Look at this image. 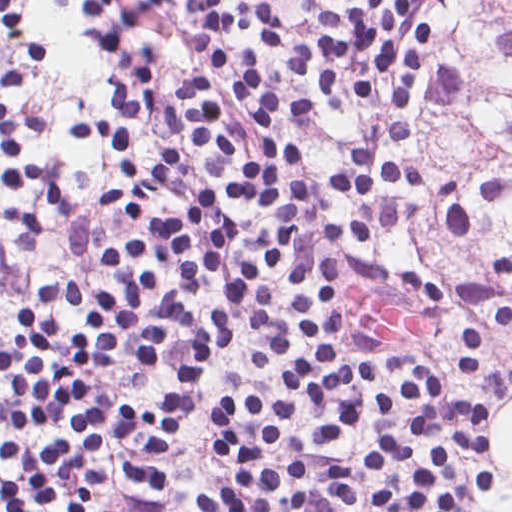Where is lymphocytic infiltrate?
<instances>
[{
    "mask_svg": "<svg viewBox=\"0 0 512 512\" xmlns=\"http://www.w3.org/2000/svg\"><path fill=\"white\" fill-rule=\"evenodd\" d=\"M88 6L84 26L96 50L112 61L98 81L108 100L97 112L74 116L69 136L117 158L122 180L103 192L104 212L129 214L146 229L106 240L104 263L112 286L83 287L55 278L39 305L81 313L74 332L28 304H13L17 330L0 348V419L22 431L73 427L74 437L32 443L11 435L0 453L16 469L0 475V512H99L96 495L109 478L92 465L107 432L144 440L161 455L192 411L208 364L236 337L230 316L250 319V330L270 352L248 356L246 369L267 375L278 354L296 347L270 287L260 278L287 249L312 212L316 193L377 197L389 185L422 191L445 226L465 235L470 207L504 201L509 189L496 176L473 198L462 182L441 180L421 163L392 160L413 124L384 126L386 146L356 148L348 165L318 176L311 150L288 141L277 124L285 107H316L308 99L272 95L265 63L249 45L227 53L221 35L267 25V6L289 0H74ZM312 12L320 40L293 59L307 76L319 69L318 100L330 104L349 72L352 92L373 96L398 72L394 102L411 109L433 40V25L403 43V23L427 0H296ZM174 10L187 23L192 67L181 80L160 77L155 43L133 57V39ZM0 24L15 52L47 63L49 42L32 30L21 0H0ZM150 119L167 127V148L141 172L137 137ZM37 113L16 115L0 101V182L58 200V181L47 165L24 159L17 140L35 132ZM139 177L125 211L117 200ZM422 219V204L404 198L364 204L352 224L324 223L321 235L352 242L381 226ZM368 280L444 303L447 292L413 271L364 259L303 254L290 268V301L303 353L290 365L288 392L240 390L211 410L219 443L213 461L229 477L197 497L201 512H305L311 470L275 453L305 451L290 424L302 403L321 449L333 450L372 419L411 411L413 426L386 434L369 447L330 463L322 472L334 493V512H472L492 488L486 421L492 402L463 396L452 380L415 355L393 350L377 364L376 344L346 330L340 278ZM146 315H177L186 354L169 388L122 396L112 410L90 379L107 356L129 340L127 358L147 368L166 356L168 326ZM406 374L403 384L375 386L379 367ZM269 455V458H265ZM104 472V471H103Z\"/></svg>",
    "mask_w": 512,
    "mask_h": 512,
    "instance_id": "1",
    "label": "lymphocytic infiltrate"
}]
</instances>
